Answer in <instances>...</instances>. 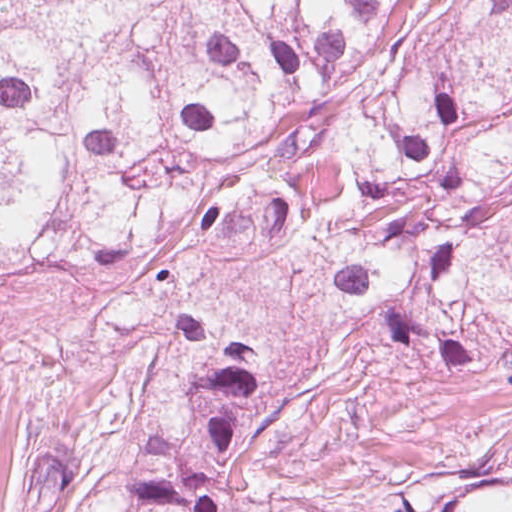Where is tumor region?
I'll use <instances>...</instances> for the list:
<instances>
[{
    "label": "tumor region",
    "instance_id": "1",
    "mask_svg": "<svg viewBox=\"0 0 512 512\" xmlns=\"http://www.w3.org/2000/svg\"><path fill=\"white\" fill-rule=\"evenodd\" d=\"M230 251L512 387V0H0V301ZM256 351L191 356L58 512H230ZM407 512H512V437Z\"/></svg>",
    "mask_w": 512,
    "mask_h": 512
}]
</instances>
